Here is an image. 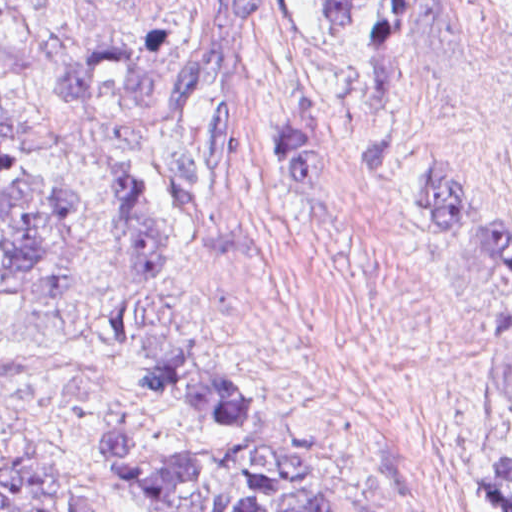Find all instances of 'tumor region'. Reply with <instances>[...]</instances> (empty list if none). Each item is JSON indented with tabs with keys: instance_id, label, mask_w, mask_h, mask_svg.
Listing matches in <instances>:
<instances>
[{
	"instance_id": "obj_1",
	"label": "tumor region",
	"mask_w": 512,
	"mask_h": 512,
	"mask_svg": "<svg viewBox=\"0 0 512 512\" xmlns=\"http://www.w3.org/2000/svg\"><path fill=\"white\" fill-rule=\"evenodd\" d=\"M328 57L366 58L386 39L381 0H292ZM193 26H144L135 49L90 39L52 76L57 98L103 97L139 116L157 103L180 118L175 141L146 158L96 132L22 139L0 132V328L40 297L128 285L175 201L185 235L221 255L256 247L244 207L248 162L233 146L229 90L243 60L240 27L263 0H194ZM0 83H12L0 69ZM280 172L304 193L328 190L321 94H287L275 116ZM419 201L446 247L512 274V231L471 205L448 167L418 168ZM221 350L172 344L140 360L132 400L105 418L119 483L147 512H347L310 453L274 426L269 395L227 380ZM478 488L512 512V385L488 436ZM0 512H83L40 482L0 499Z\"/></svg>"
}]
</instances>
